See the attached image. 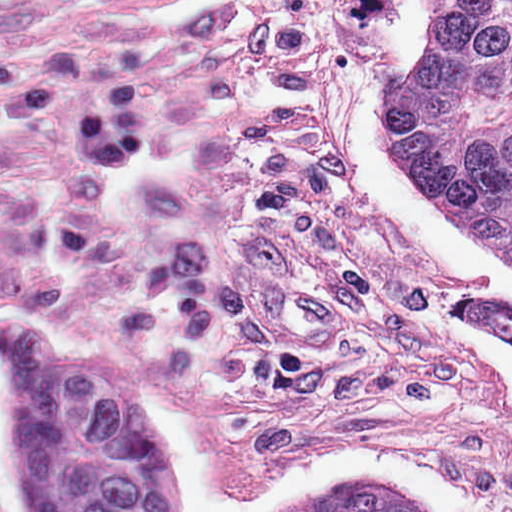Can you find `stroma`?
<instances>
[{
  "label": "stroma",
  "mask_w": 512,
  "mask_h": 512,
  "mask_svg": "<svg viewBox=\"0 0 512 512\" xmlns=\"http://www.w3.org/2000/svg\"><path fill=\"white\" fill-rule=\"evenodd\" d=\"M478 512H512V340L457 303L512 292V261L422 190L389 72L432 41L428 0H250Z\"/></svg>",
  "instance_id": "1"
}]
</instances>
